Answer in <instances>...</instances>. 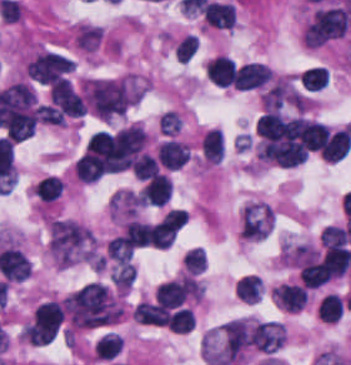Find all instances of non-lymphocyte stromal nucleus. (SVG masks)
I'll return each instance as SVG.
<instances>
[{
    "label": "non-lymphocyte stromal nucleus",
    "mask_w": 351,
    "mask_h": 365,
    "mask_svg": "<svg viewBox=\"0 0 351 365\" xmlns=\"http://www.w3.org/2000/svg\"><path fill=\"white\" fill-rule=\"evenodd\" d=\"M49 246L60 267L92 258L91 232L70 219H56L52 223Z\"/></svg>",
    "instance_id": "1"
}]
</instances>
